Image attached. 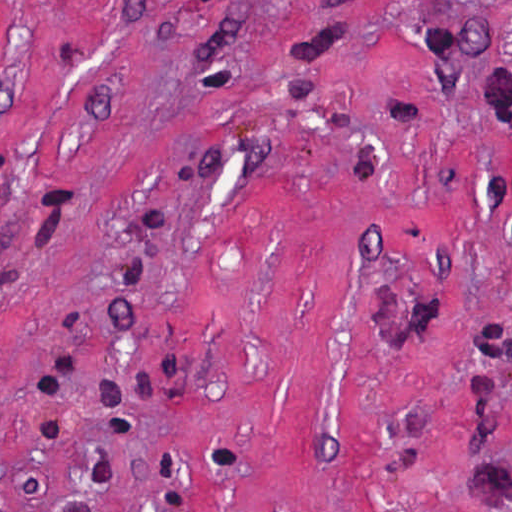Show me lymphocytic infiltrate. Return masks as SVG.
<instances>
[{"label": "lymphocytic infiltrate", "instance_id": "obj_1", "mask_svg": "<svg viewBox=\"0 0 512 512\" xmlns=\"http://www.w3.org/2000/svg\"><path fill=\"white\" fill-rule=\"evenodd\" d=\"M76 369V353L68 351L57 368L37 376L39 395L46 401L43 409L44 435L51 443L62 435L61 423L50 412V403L60 399L61 389Z\"/></svg>", "mask_w": 512, "mask_h": 512}]
</instances>
